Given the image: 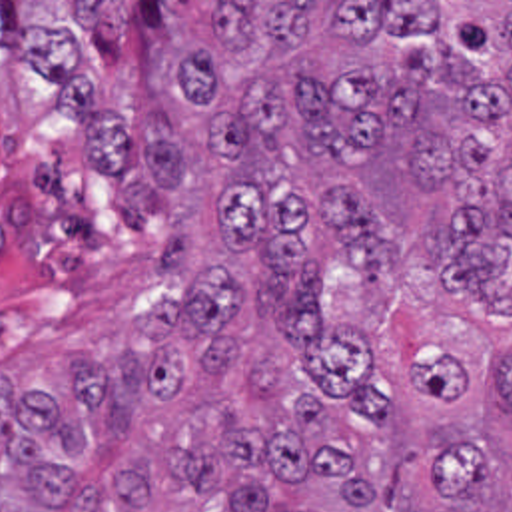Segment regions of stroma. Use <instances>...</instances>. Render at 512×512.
I'll list each match as a JSON object with an SVG mask.
<instances>
[{"instance_id": "1", "label": "stroma", "mask_w": 512, "mask_h": 512, "mask_svg": "<svg viewBox=\"0 0 512 512\" xmlns=\"http://www.w3.org/2000/svg\"><path fill=\"white\" fill-rule=\"evenodd\" d=\"M26 2H121L123 50L115 64L99 60L97 92L119 112L121 126L145 142L151 122L149 74L173 50L175 26L169 2H512V0H0V40L22 54V10ZM493 138L499 148L512 144V94ZM325 268L445 349L489 381L491 349L512 343V307H487L473 291L447 289L437 281L431 250L417 240L393 246V268L379 279H363L349 260Z\"/></svg>"}]
</instances>
